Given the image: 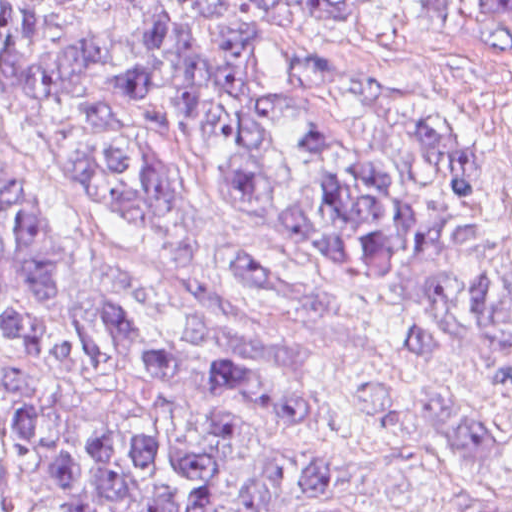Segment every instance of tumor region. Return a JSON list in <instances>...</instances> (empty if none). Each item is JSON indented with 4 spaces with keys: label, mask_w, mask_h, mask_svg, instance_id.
I'll return each instance as SVG.
<instances>
[{
    "label": "tumor region",
    "mask_w": 512,
    "mask_h": 512,
    "mask_svg": "<svg viewBox=\"0 0 512 512\" xmlns=\"http://www.w3.org/2000/svg\"><path fill=\"white\" fill-rule=\"evenodd\" d=\"M138 43L118 87L158 98L208 149L221 193L272 233L311 245L360 287L413 283L406 340L424 355L462 348L492 388L512 389V194L469 136L443 120L374 102L333 74L335 55L298 51L275 82L253 75L251 39L207 36L218 0H125ZM349 20L332 0H260ZM512 115V84L506 98ZM0 122L64 178L137 203L166 231L179 185L165 161L126 141L100 87L95 52L58 0H0ZM207 276L261 305L275 275L258 255L226 250ZM126 369L165 405L184 383L313 434L306 452L226 415L188 444L140 431L84 441L57 460L67 512H213L229 461L259 473L240 512H397L360 505L334 477L328 427L294 374L219 347L167 297L94 268L58 202L0 166V496L44 424L32 400L43 372ZM461 445L449 501L458 511L500 464V433L454 418Z\"/></svg>",
    "instance_id": "obj_1"
}]
</instances>
